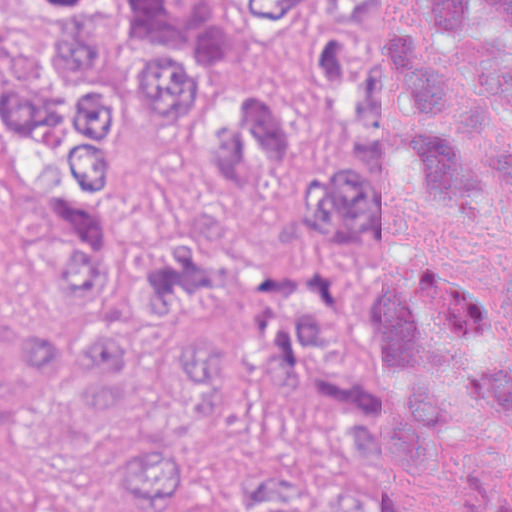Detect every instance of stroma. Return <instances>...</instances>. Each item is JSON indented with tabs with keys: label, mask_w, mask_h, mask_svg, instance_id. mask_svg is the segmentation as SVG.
<instances>
[{
	"label": "stroma",
	"mask_w": 512,
	"mask_h": 512,
	"mask_svg": "<svg viewBox=\"0 0 512 512\" xmlns=\"http://www.w3.org/2000/svg\"><path fill=\"white\" fill-rule=\"evenodd\" d=\"M0 299L14 313L28 299V249L23 201L0 172ZM506 453L492 440L459 445L410 479L413 512H460L469 492L501 484Z\"/></svg>",
	"instance_id": "stroma-1"
}]
</instances>
